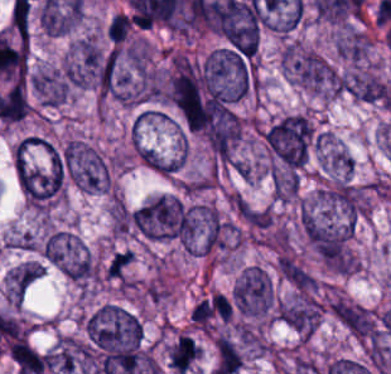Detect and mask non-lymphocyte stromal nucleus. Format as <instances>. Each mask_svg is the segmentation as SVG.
I'll return each instance as SVG.
<instances>
[{
  "mask_svg": "<svg viewBox=\"0 0 391 374\" xmlns=\"http://www.w3.org/2000/svg\"><path fill=\"white\" fill-rule=\"evenodd\" d=\"M280 276L302 290H312L314 280L307 271L289 255H282L278 262Z\"/></svg>",
  "mask_w": 391,
  "mask_h": 374,
  "instance_id": "obj_1",
  "label": "non-lymphocyte stromal nucleus"
}]
</instances>
